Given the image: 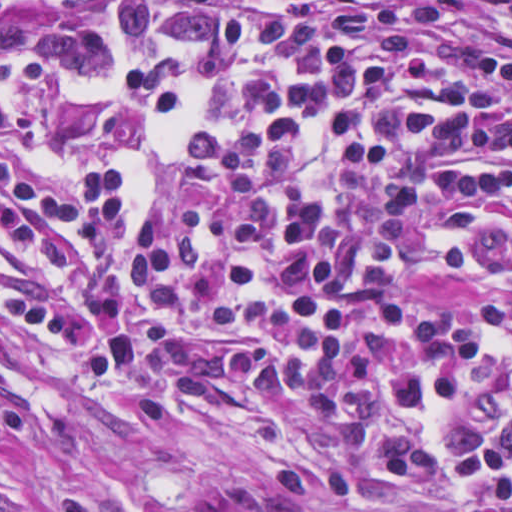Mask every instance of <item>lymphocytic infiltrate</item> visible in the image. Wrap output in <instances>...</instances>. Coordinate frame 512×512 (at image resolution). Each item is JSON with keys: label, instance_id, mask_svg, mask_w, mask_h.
I'll return each instance as SVG.
<instances>
[{"label": "lymphocytic infiltrate", "instance_id": "lymphocytic-infiltrate-1", "mask_svg": "<svg viewBox=\"0 0 512 512\" xmlns=\"http://www.w3.org/2000/svg\"><path fill=\"white\" fill-rule=\"evenodd\" d=\"M28 72L189 127L148 216L107 168L1 165L10 361L87 392L288 394L464 357L512 318V43L463 8L137 0L109 54ZM328 407L217 470L213 512H512V335L441 404Z\"/></svg>", "mask_w": 512, "mask_h": 512}]
</instances>
